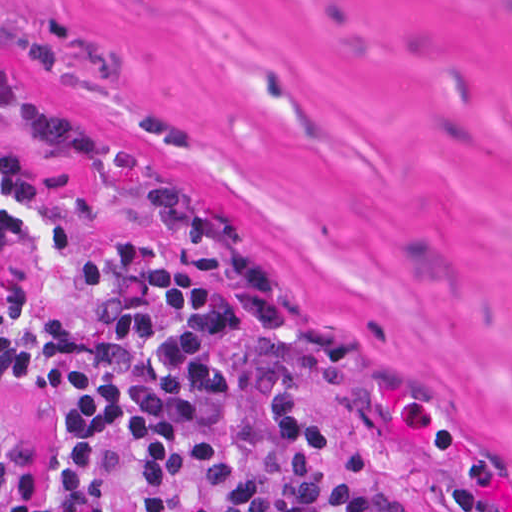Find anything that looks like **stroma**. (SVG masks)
Returning <instances> with one entry per match:
<instances>
[{
  "label": "stroma",
  "instance_id": "obj_1",
  "mask_svg": "<svg viewBox=\"0 0 512 512\" xmlns=\"http://www.w3.org/2000/svg\"><path fill=\"white\" fill-rule=\"evenodd\" d=\"M0 107L75 135L429 512H512V0H0ZM57 405L0 371L24 492Z\"/></svg>",
  "mask_w": 512,
  "mask_h": 512
}]
</instances>
